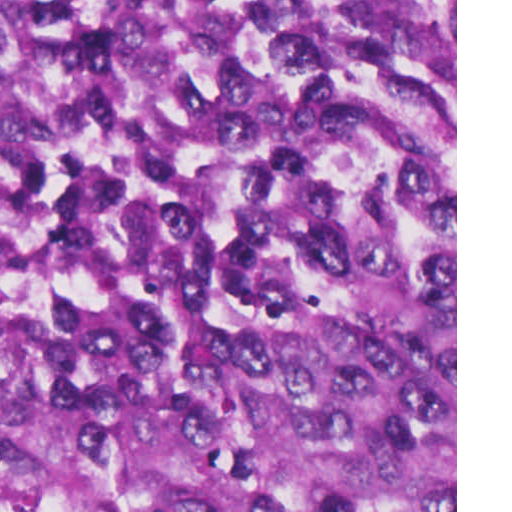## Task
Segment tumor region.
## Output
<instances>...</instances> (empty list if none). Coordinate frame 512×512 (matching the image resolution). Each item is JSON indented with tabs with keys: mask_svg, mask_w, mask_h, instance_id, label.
Masks as SVG:
<instances>
[{
	"mask_svg": "<svg viewBox=\"0 0 512 512\" xmlns=\"http://www.w3.org/2000/svg\"><path fill=\"white\" fill-rule=\"evenodd\" d=\"M0 512H455V0H0Z\"/></svg>",
	"mask_w": 512,
	"mask_h": 512,
	"instance_id": "e687c5a6",
	"label": "tumor region"
}]
</instances>
